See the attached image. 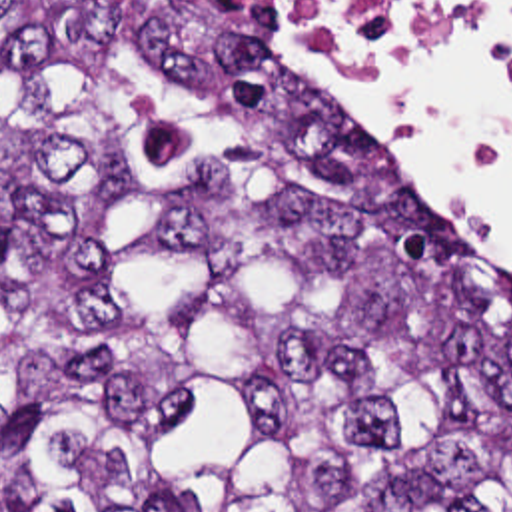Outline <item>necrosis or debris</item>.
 Returning a JSON list of instances; mask_svg holds the SVG:
<instances>
[{
    "instance_id": "4bbe7bcc",
    "label": "necrosis or debris",
    "mask_w": 512,
    "mask_h": 512,
    "mask_svg": "<svg viewBox=\"0 0 512 512\" xmlns=\"http://www.w3.org/2000/svg\"><path fill=\"white\" fill-rule=\"evenodd\" d=\"M286 6L361 60L441 12H463L479 18L501 48L512 52V2L501 6H459L449 0H286Z\"/></svg>"
}]
</instances>
